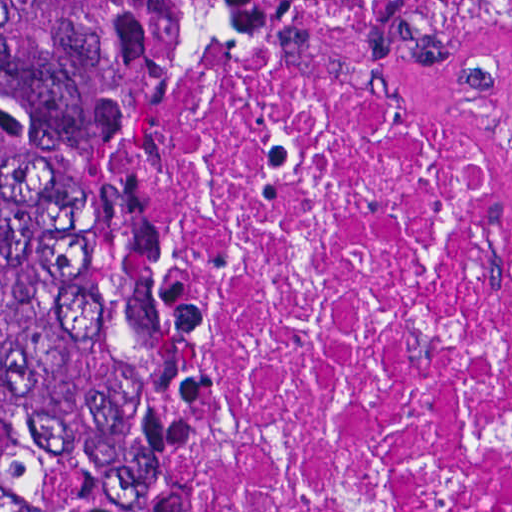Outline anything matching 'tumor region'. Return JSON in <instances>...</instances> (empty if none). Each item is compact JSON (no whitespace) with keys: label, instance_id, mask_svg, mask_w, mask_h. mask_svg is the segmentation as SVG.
<instances>
[{"label":"tumor region","instance_id":"tumor-region-1","mask_svg":"<svg viewBox=\"0 0 512 512\" xmlns=\"http://www.w3.org/2000/svg\"><path fill=\"white\" fill-rule=\"evenodd\" d=\"M234 0H0V512L168 501L190 409L142 239V98Z\"/></svg>","mask_w":512,"mask_h":512}]
</instances>
